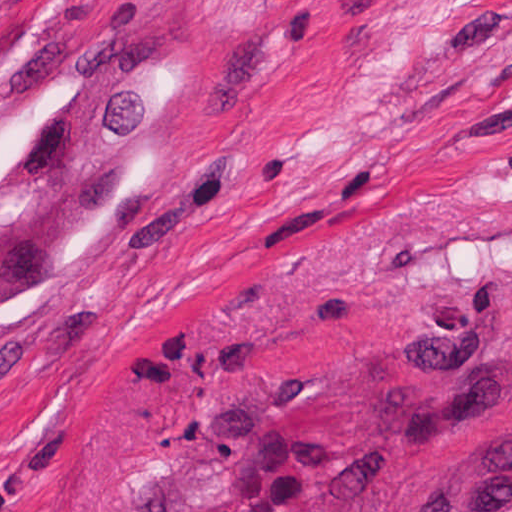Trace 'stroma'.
<instances>
[{"label": "stroma", "instance_id": "35a3bbf8", "mask_svg": "<svg viewBox=\"0 0 512 512\" xmlns=\"http://www.w3.org/2000/svg\"><path fill=\"white\" fill-rule=\"evenodd\" d=\"M0 512H512V0H0Z\"/></svg>", "mask_w": 512, "mask_h": 512}]
</instances>
